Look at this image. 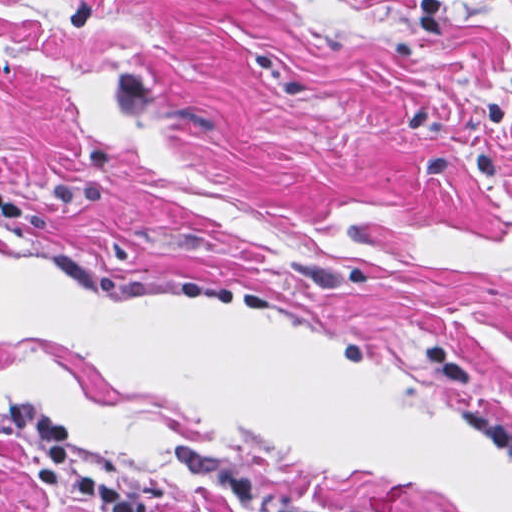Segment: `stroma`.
Masks as SVG:
<instances>
[{"mask_svg": "<svg viewBox=\"0 0 512 512\" xmlns=\"http://www.w3.org/2000/svg\"><path fill=\"white\" fill-rule=\"evenodd\" d=\"M0 406L159 512H512V0H0ZM0 512H83L0 434Z\"/></svg>", "mask_w": 512, "mask_h": 512, "instance_id": "obj_1", "label": "stroma"}]
</instances>
